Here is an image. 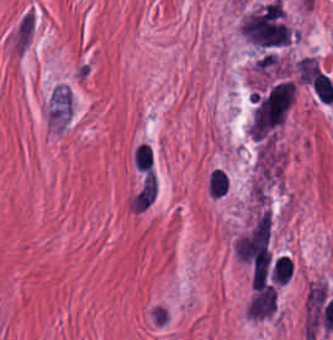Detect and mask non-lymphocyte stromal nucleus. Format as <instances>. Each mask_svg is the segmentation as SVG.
<instances>
[{"mask_svg": "<svg viewBox=\"0 0 333 340\" xmlns=\"http://www.w3.org/2000/svg\"><path fill=\"white\" fill-rule=\"evenodd\" d=\"M72 112V96L67 86L57 84L50 95L48 121L57 129H64Z\"/></svg>", "mask_w": 333, "mask_h": 340, "instance_id": "obj_1", "label": "non-lymphocyte stromal nucleus"}]
</instances>
